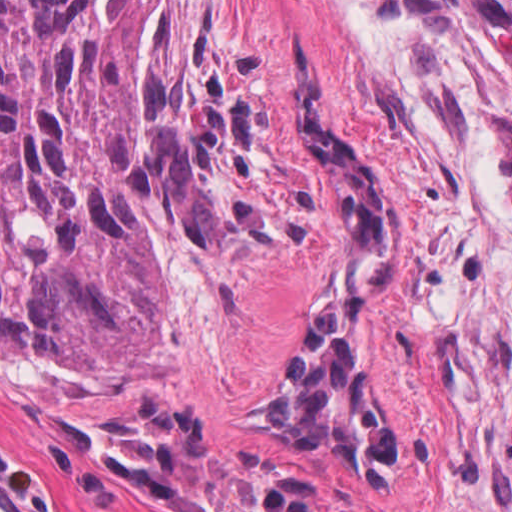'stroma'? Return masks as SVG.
<instances>
[{
	"label": "stroma",
	"instance_id": "stroma-1",
	"mask_svg": "<svg viewBox=\"0 0 512 512\" xmlns=\"http://www.w3.org/2000/svg\"><path fill=\"white\" fill-rule=\"evenodd\" d=\"M241 54L308 190V219L274 248L167 240L164 330L131 384H81L0 350V433L48 512H215L156 495L91 435L160 397L224 464L299 485L349 512H512V198L496 136L512 104L463 56L369 34L343 0H199ZM400 187V261L377 319L400 452L383 479H344L310 451L245 434L274 406L342 235L292 129V47ZM0 512H38L0 482Z\"/></svg>",
	"mask_w": 512,
	"mask_h": 512
}]
</instances>
